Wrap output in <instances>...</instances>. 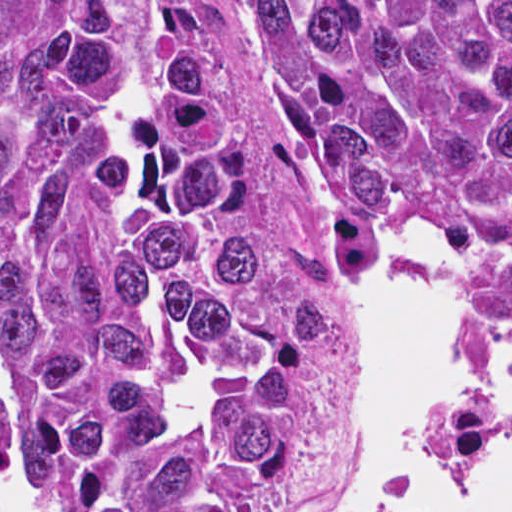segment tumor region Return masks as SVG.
<instances>
[{"mask_svg": "<svg viewBox=\"0 0 512 512\" xmlns=\"http://www.w3.org/2000/svg\"><path fill=\"white\" fill-rule=\"evenodd\" d=\"M363 284L440 234L512 348V0H253ZM0 341L49 512H275L335 341L170 0H0Z\"/></svg>", "mask_w": 512, "mask_h": 512, "instance_id": "1", "label": "tumor region"}]
</instances>
